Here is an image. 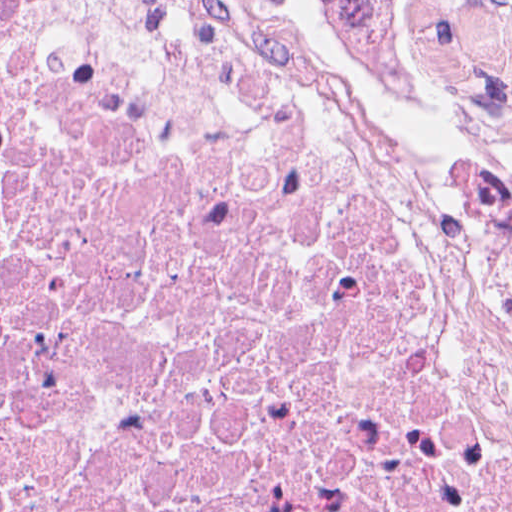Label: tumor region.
<instances>
[{
    "label": "tumor region",
    "instance_id": "tumor-region-1",
    "mask_svg": "<svg viewBox=\"0 0 512 512\" xmlns=\"http://www.w3.org/2000/svg\"><path fill=\"white\" fill-rule=\"evenodd\" d=\"M357 63L392 98L438 128H486L507 116L487 113L472 97L447 93L418 57L395 50L347 20L331 3L311 0Z\"/></svg>",
    "mask_w": 512,
    "mask_h": 512
}]
</instances>
